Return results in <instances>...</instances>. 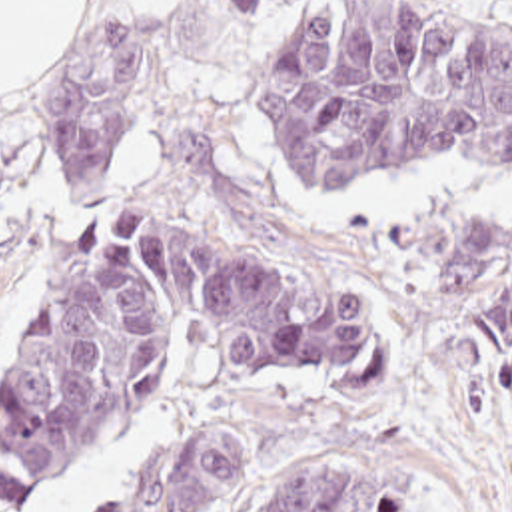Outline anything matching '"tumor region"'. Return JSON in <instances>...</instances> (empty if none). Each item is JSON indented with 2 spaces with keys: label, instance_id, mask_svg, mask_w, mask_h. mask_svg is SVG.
<instances>
[{
  "label": "tumor region",
  "instance_id": "e687c5a6",
  "mask_svg": "<svg viewBox=\"0 0 512 512\" xmlns=\"http://www.w3.org/2000/svg\"><path fill=\"white\" fill-rule=\"evenodd\" d=\"M263 1V0H235ZM241 103L301 191L470 163L512 179V15L444 0H318L239 81ZM137 31L91 29L57 71L51 165L93 195L135 117ZM442 309L486 371H512V219L424 213ZM211 345L241 379L316 371L360 345V305L199 227L103 213L69 241L51 297L0 385V512L123 423L181 351ZM247 482V449L201 429L95 512H209ZM237 512H428L364 452L299 460Z\"/></svg>",
  "mask_w": 512,
  "mask_h": 512
}]
</instances>
